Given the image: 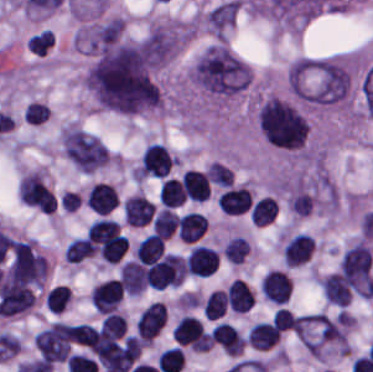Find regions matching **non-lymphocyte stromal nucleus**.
<instances>
[{
	"mask_svg": "<svg viewBox=\"0 0 373 372\" xmlns=\"http://www.w3.org/2000/svg\"><path fill=\"white\" fill-rule=\"evenodd\" d=\"M224 259L229 264H242L249 254V243L241 235H234L222 248Z\"/></svg>",
	"mask_w": 373,
	"mask_h": 372,
	"instance_id": "6",
	"label": "non-lymphocyte stromal nucleus"
},
{
	"mask_svg": "<svg viewBox=\"0 0 373 372\" xmlns=\"http://www.w3.org/2000/svg\"><path fill=\"white\" fill-rule=\"evenodd\" d=\"M60 139L64 156L81 172L92 174L109 160L103 141L79 126L64 127Z\"/></svg>",
	"mask_w": 373,
	"mask_h": 372,
	"instance_id": "1",
	"label": "non-lymphocyte stromal nucleus"
},
{
	"mask_svg": "<svg viewBox=\"0 0 373 372\" xmlns=\"http://www.w3.org/2000/svg\"><path fill=\"white\" fill-rule=\"evenodd\" d=\"M89 296L94 310L99 313L115 311L123 297L118 277L97 282Z\"/></svg>",
	"mask_w": 373,
	"mask_h": 372,
	"instance_id": "2",
	"label": "non-lymphocyte stromal nucleus"
},
{
	"mask_svg": "<svg viewBox=\"0 0 373 372\" xmlns=\"http://www.w3.org/2000/svg\"><path fill=\"white\" fill-rule=\"evenodd\" d=\"M121 289L125 295H139L146 288L145 270L136 260L122 263L118 269Z\"/></svg>",
	"mask_w": 373,
	"mask_h": 372,
	"instance_id": "5",
	"label": "non-lymphocyte stromal nucleus"
},
{
	"mask_svg": "<svg viewBox=\"0 0 373 372\" xmlns=\"http://www.w3.org/2000/svg\"><path fill=\"white\" fill-rule=\"evenodd\" d=\"M211 340L226 355L235 357L241 354L245 344L235 326L221 321L211 328Z\"/></svg>",
	"mask_w": 373,
	"mask_h": 372,
	"instance_id": "4",
	"label": "non-lymphocyte stromal nucleus"
},
{
	"mask_svg": "<svg viewBox=\"0 0 373 372\" xmlns=\"http://www.w3.org/2000/svg\"><path fill=\"white\" fill-rule=\"evenodd\" d=\"M155 205L140 193H133L123 199L122 217L125 225H145L154 214Z\"/></svg>",
	"mask_w": 373,
	"mask_h": 372,
	"instance_id": "3",
	"label": "non-lymphocyte stromal nucleus"
}]
</instances>
